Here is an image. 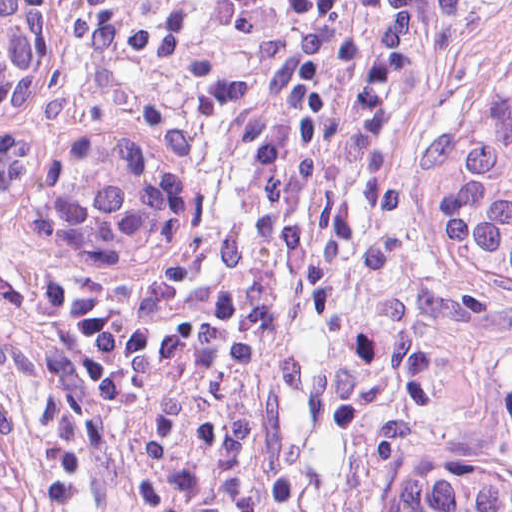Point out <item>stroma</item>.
<instances>
[{"mask_svg":"<svg viewBox=\"0 0 512 512\" xmlns=\"http://www.w3.org/2000/svg\"><path fill=\"white\" fill-rule=\"evenodd\" d=\"M47 1L102 82L141 101L119 61L81 29L75 0ZM511 55L512 0H398L320 156V195L269 320L255 473L438 255L418 214L422 106ZM189 189L190 236L169 275L114 302L80 333L42 512L114 425L156 327L196 265ZM72 267L51 246L38 189L0 196L3 390L37 397L54 385L84 308L85 279Z\"/></svg>","mask_w":512,"mask_h":512,"instance_id":"1","label":"stroma"}]
</instances>
